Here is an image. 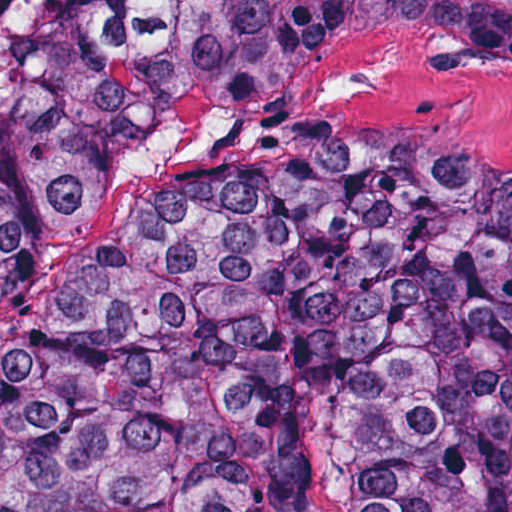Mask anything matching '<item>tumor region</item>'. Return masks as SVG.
Listing matches in <instances>:
<instances>
[{
  "instance_id": "e687c5a6",
  "label": "tumor region",
  "mask_w": 512,
  "mask_h": 512,
  "mask_svg": "<svg viewBox=\"0 0 512 512\" xmlns=\"http://www.w3.org/2000/svg\"><path fill=\"white\" fill-rule=\"evenodd\" d=\"M512 75V0H0V300L204 107L353 34ZM512 512V172L270 137L153 187L0 338V512Z\"/></svg>"
}]
</instances>
